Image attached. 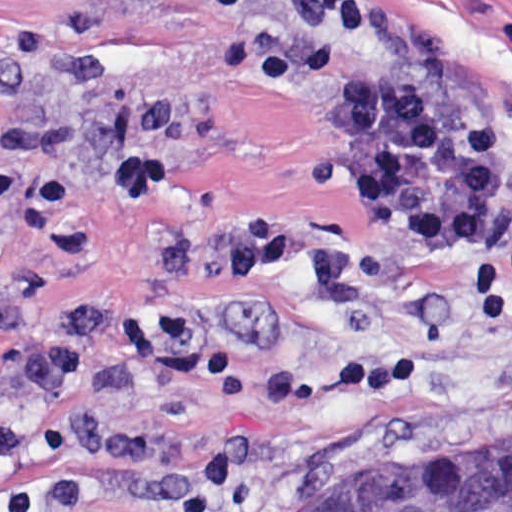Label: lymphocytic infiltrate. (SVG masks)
I'll use <instances>...</instances> for the list:
<instances>
[{"mask_svg": "<svg viewBox=\"0 0 512 512\" xmlns=\"http://www.w3.org/2000/svg\"><path fill=\"white\" fill-rule=\"evenodd\" d=\"M426 345L399 339L335 360L326 367H286L267 376L262 394L271 403H298L336 390H386L421 374Z\"/></svg>", "mask_w": 512, "mask_h": 512, "instance_id": "lymphocytic-infiltrate-1", "label": "lymphocytic infiltrate"}]
</instances>
